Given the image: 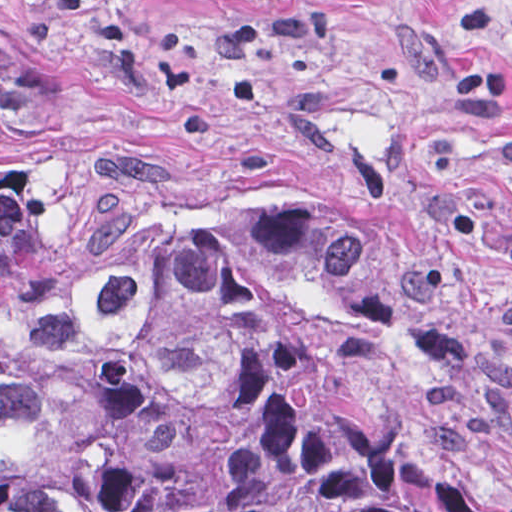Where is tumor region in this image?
<instances>
[{
  "mask_svg": "<svg viewBox=\"0 0 512 512\" xmlns=\"http://www.w3.org/2000/svg\"><path fill=\"white\" fill-rule=\"evenodd\" d=\"M415 317L361 231L192 192L0 32V512H512L393 436L328 349Z\"/></svg>",
  "mask_w": 512,
  "mask_h": 512,
  "instance_id": "tumor-region-1",
  "label": "tumor region"
}]
</instances>
